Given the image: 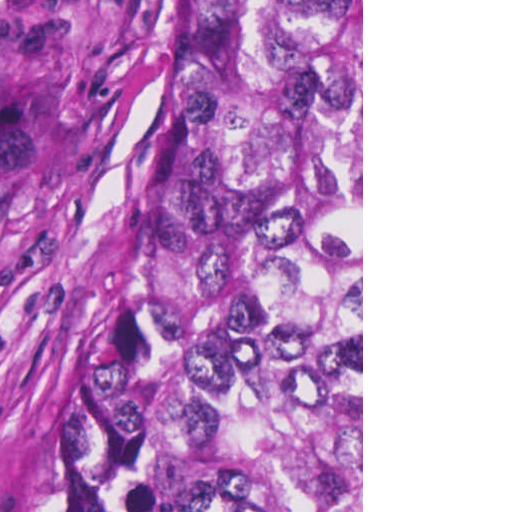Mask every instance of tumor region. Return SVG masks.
<instances>
[{"instance_id": "e687c5a6", "label": "tumor region", "mask_w": 512, "mask_h": 512, "mask_svg": "<svg viewBox=\"0 0 512 512\" xmlns=\"http://www.w3.org/2000/svg\"><path fill=\"white\" fill-rule=\"evenodd\" d=\"M13 512H361V0H185L132 253Z\"/></svg>"}]
</instances>
